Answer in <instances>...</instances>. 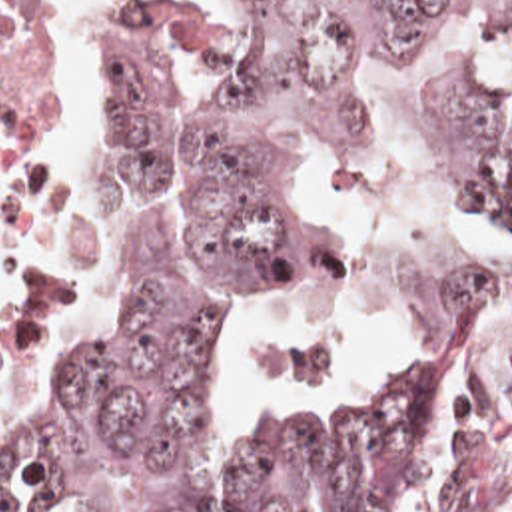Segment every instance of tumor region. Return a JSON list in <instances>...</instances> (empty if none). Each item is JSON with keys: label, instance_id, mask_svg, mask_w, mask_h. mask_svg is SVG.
Masks as SVG:
<instances>
[{"label": "tumor region", "instance_id": "tumor-region-1", "mask_svg": "<svg viewBox=\"0 0 512 512\" xmlns=\"http://www.w3.org/2000/svg\"><path fill=\"white\" fill-rule=\"evenodd\" d=\"M494 2L243 0L215 90L197 20L109 2L99 144L123 180L117 284L61 397L0 447V512H512V280L456 294L388 383L303 413L237 481L215 475L201 403L205 344L249 288L341 280L343 240L297 202V172L319 140L374 146L354 68ZM462 164L512 230V114H470Z\"/></svg>", "mask_w": 512, "mask_h": 512}]
</instances>
